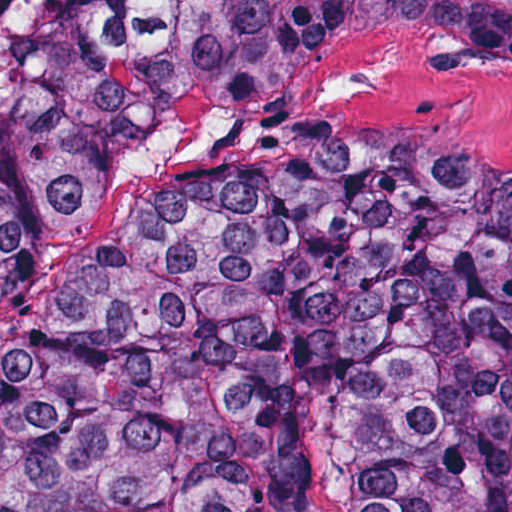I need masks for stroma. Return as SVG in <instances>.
<instances>
[{
	"mask_svg": "<svg viewBox=\"0 0 512 512\" xmlns=\"http://www.w3.org/2000/svg\"><path fill=\"white\" fill-rule=\"evenodd\" d=\"M270 137H425L473 163L512 172V75L474 66L402 30L353 34L301 61L261 96L204 107L110 183L71 248L0 300V338L99 268L154 186L181 168ZM315 512H348L339 443L321 439Z\"/></svg>",
	"mask_w": 512,
	"mask_h": 512,
	"instance_id": "obj_1",
	"label": "stroma"
}]
</instances>
